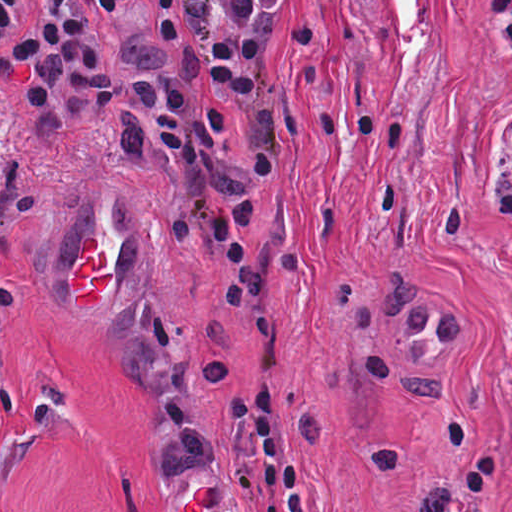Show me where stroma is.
<instances>
[{"label": "stroma", "instance_id": "35a3bbf8", "mask_svg": "<svg viewBox=\"0 0 512 512\" xmlns=\"http://www.w3.org/2000/svg\"><path fill=\"white\" fill-rule=\"evenodd\" d=\"M18 0L0 59L40 26ZM281 273L222 379L224 296L114 127L42 140L0 91V512H182L260 478L228 399L266 377L290 464L512 365V66L483 0H289L266 121ZM96 239V305L69 277ZM127 298L108 337L100 302Z\"/></svg>", "mask_w": 512, "mask_h": 512}]
</instances>
